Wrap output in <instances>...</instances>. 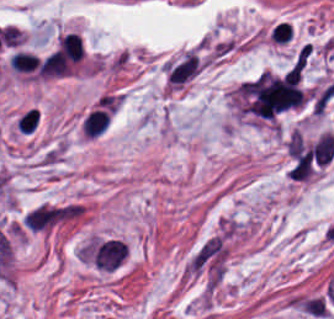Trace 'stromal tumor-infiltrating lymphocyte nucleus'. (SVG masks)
<instances>
[{
	"label": "stromal tumor-infiltrating lymphocyte nucleus",
	"instance_id": "obj_1",
	"mask_svg": "<svg viewBox=\"0 0 334 319\" xmlns=\"http://www.w3.org/2000/svg\"><path fill=\"white\" fill-rule=\"evenodd\" d=\"M59 49L74 64L83 58L84 50L79 33L67 32L59 38Z\"/></svg>",
	"mask_w": 334,
	"mask_h": 319
},
{
	"label": "stromal tumor-infiltrating lymphocyte nucleus",
	"instance_id": "obj_3",
	"mask_svg": "<svg viewBox=\"0 0 334 319\" xmlns=\"http://www.w3.org/2000/svg\"><path fill=\"white\" fill-rule=\"evenodd\" d=\"M40 120V113L36 107H29L19 117L17 127L20 132H34Z\"/></svg>",
	"mask_w": 334,
	"mask_h": 319
},
{
	"label": "stromal tumor-infiltrating lymphocyte nucleus",
	"instance_id": "obj_2",
	"mask_svg": "<svg viewBox=\"0 0 334 319\" xmlns=\"http://www.w3.org/2000/svg\"><path fill=\"white\" fill-rule=\"evenodd\" d=\"M39 59L37 55L24 50H17L9 62L15 72H30L37 69Z\"/></svg>",
	"mask_w": 334,
	"mask_h": 319
}]
</instances>
